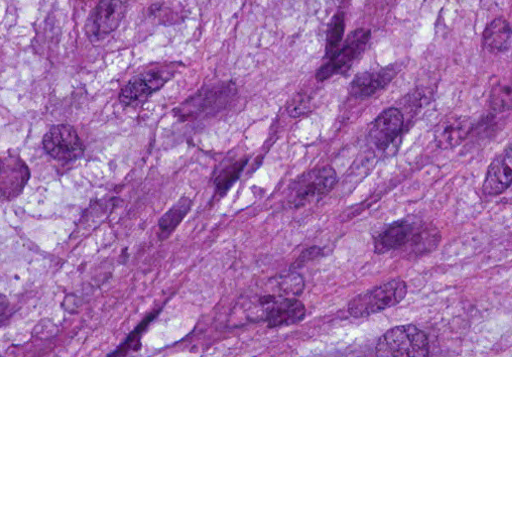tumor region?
Instances as JSON below:
<instances>
[{
    "label": "tumor region",
    "mask_w": 512,
    "mask_h": 512,
    "mask_svg": "<svg viewBox=\"0 0 512 512\" xmlns=\"http://www.w3.org/2000/svg\"><path fill=\"white\" fill-rule=\"evenodd\" d=\"M0 356H512V0H0Z\"/></svg>",
    "instance_id": "1"
}]
</instances>
